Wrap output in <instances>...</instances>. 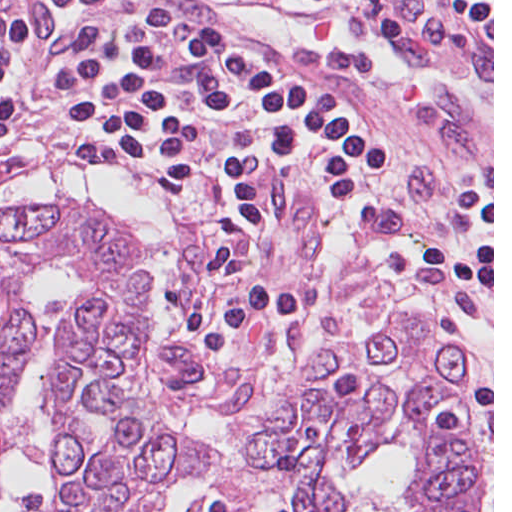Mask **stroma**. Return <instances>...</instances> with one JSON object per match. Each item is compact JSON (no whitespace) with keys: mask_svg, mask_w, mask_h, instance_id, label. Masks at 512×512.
<instances>
[{"mask_svg":"<svg viewBox=\"0 0 512 512\" xmlns=\"http://www.w3.org/2000/svg\"><path fill=\"white\" fill-rule=\"evenodd\" d=\"M58 0H0V10L15 16H35L44 21L56 16ZM29 29V28H25Z\"/></svg>","mask_w":512,"mask_h":512,"instance_id":"1","label":"stroma"}]
</instances>
